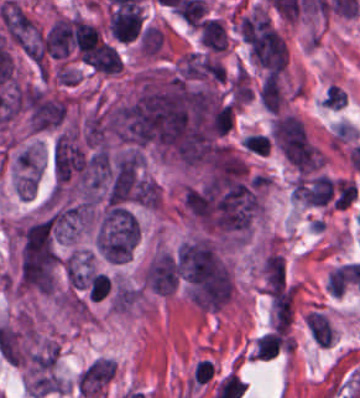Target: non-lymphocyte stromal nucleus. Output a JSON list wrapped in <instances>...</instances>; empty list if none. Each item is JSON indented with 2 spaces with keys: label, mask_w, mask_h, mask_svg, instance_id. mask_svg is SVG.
<instances>
[{
  "label": "non-lymphocyte stromal nucleus",
  "mask_w": 360,
  "mask_h": 398,
  "mask_svg": "<svg viewBox=\"0 0 360 398\" xmlns=\"http://www.w3.org/2000/svg\"><path fill=\"white\" fill-rule=\"evenodd\" d=\"M260 99L266 109L278 111L282 96L275 74L270 72L263 79Z\"/></svg>",
  "instance_id": "a72fc3eb"
},
{
  "label": "non-lymphocyte stromal nucleus",
  "mask_w": 360,
  "mask_h": 398,
  "mask_svg": "<svg viewBox=\"0 0 360 398\" xmlns=\"http://www.w3.org/2000/svg\"><path fill=\"white\" fill-rule=\"evenodd\" d=\"M307 323L314 341L319 346H330L333 328L328 316L323 311H309Z\"/></svg>",
  "instance_id": "dd21d789"
}]
</instances>
